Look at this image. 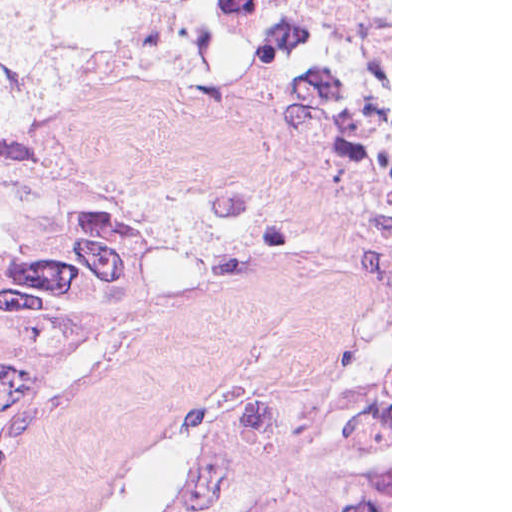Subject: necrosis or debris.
I'll return each instance as SVG.
<instances>
[{"label": "necrosis or debris", "instance_id": "4bbe7bcc", "mask_svg": "<svg viewBox=\"0 0 512 512\" xmlns=\"http://www.w3.org/2000/svg\"><path fill=\"white\" fill-rule=\"evenodd\" d=\"M172 11L222 21H306L391 6V0H147Z\"/></svg>", "mask_w": 512, "mask_h": 512}]
</instances>
